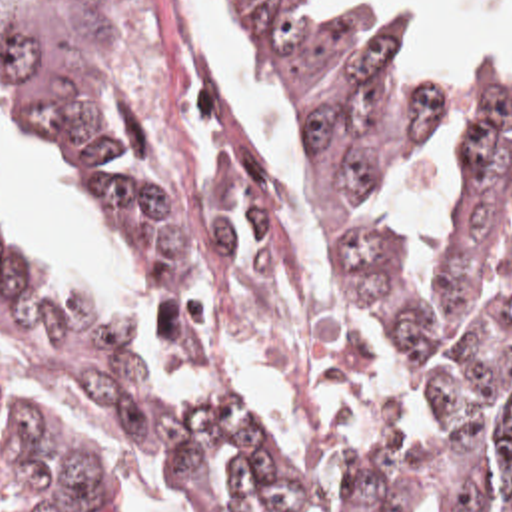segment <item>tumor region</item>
Wrapping results in <instances>:
<instances>
[{
  "label": "tumor region",
  "instance_id": "1",
  "mask_svg": "<svg viewBox=\"0 0 512 512\" xmlns=\"http://www.w3.org/2000/svg\"><path fill=\"white\" fill-rule=\"evenodd\" d=\"M255 0L265 65L307 139L349 289L421 375V430L391 466L335 460L339 512H512V245L495 249L512 169V85H493L465 125L453 267L417 299L395 233L363 213L383 171L449 107L441 83L399 61L407 19L373 5L291 17ZM0 73L27 115L99 183L137 273L185 291L215 279L233 299V239L219 207L141 145L119 75V25L103 0H0ZM47 293L33 259L0 245V333L33 325ZM67 401L177 482L199 512H307L295 466L249 393L173 391L135 349L83 313L65 347ZM18 512H111L89 454L41 417L0 424V504Z\"/></svg>",
  "mask_w": 512,
  "mask_h": 512
}]
</instances>
